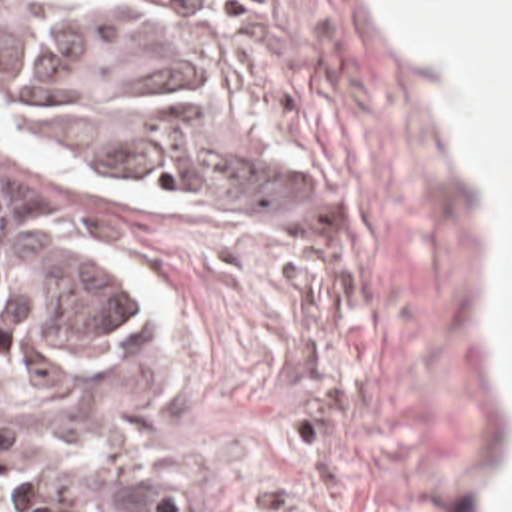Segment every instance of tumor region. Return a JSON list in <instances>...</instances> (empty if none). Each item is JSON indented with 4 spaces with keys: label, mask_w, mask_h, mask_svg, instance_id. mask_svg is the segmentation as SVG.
Wrapping results in <instances>:
<instances>
[{
    "label": "tumor region",
    "mask_w": 512,
    "mask_h": 512,
    "mask_svg": "<svg viewBox=\"0 0 512 512\" xmlns=\"http://www.w3.org/2000/svg\"><path fill=\"white\" fill-rule=\"evenodd\" d=\"M151 310L111 240L69 214H0V491L9 512H211L153 474L61 450L25 402L131 364Z\"/></svg>",
    "instance_id": "tumor-region-1"
}]
</instances>
